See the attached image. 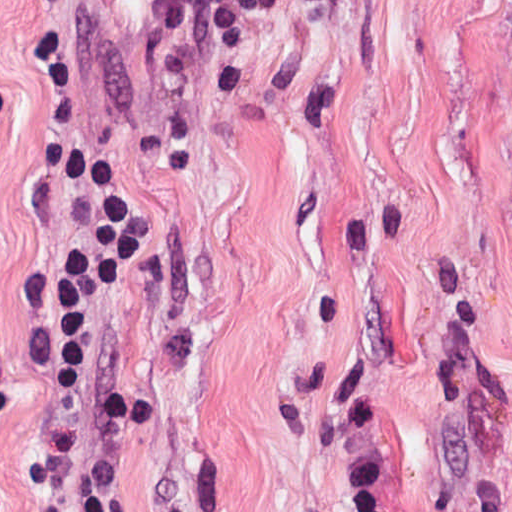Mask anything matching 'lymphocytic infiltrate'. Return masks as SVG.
I'll return each mask as SVG.
<instances>
[{"mask_svg":"<svg viewBox=\"0 0 512 512\" xmlns=\"http://www.w3.org/2000/svg\"><path fill=\"white\" fill-rule=\"evenodd\" d=\"M45 132L69 138L73 163V250L64 286V340L57 375L60 431L81 442L86 428V359L93 333L131 283L144 256L137 203L98 148L70 138L74 66L53 38L33 41Z\"/></svg>","mask_w":512,"mask_h":512,"instance_id":"f902f5d3","label":"lymphocytic infiltrate"}]
</instances>
